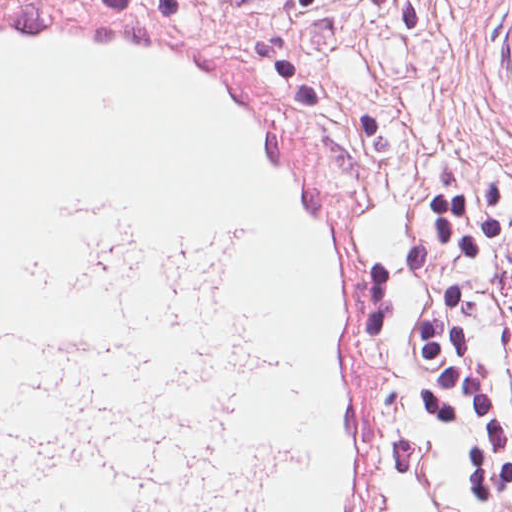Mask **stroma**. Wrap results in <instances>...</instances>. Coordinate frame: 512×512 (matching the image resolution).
<instances>
[{"label": "stroma", "instance_id": "obj_1", "mask_svg": "<svg viewBox=\"0 0 512 512\" xmlns=\"http://www.w3.org/2000/svg\"><path fill=\"white\" fill-rule=\"evenodd\" d=\"M130 5L233 50L324 123L367 178L395 265L430 177L446 161L512 167V0H0ZM507 320L512 322V298ZM306 448V414H305ZM378 512H512L452 479L386 477L378 407Z\"/></svg>", "mask_w": 512, "mask_h": 512}]
</instances>
